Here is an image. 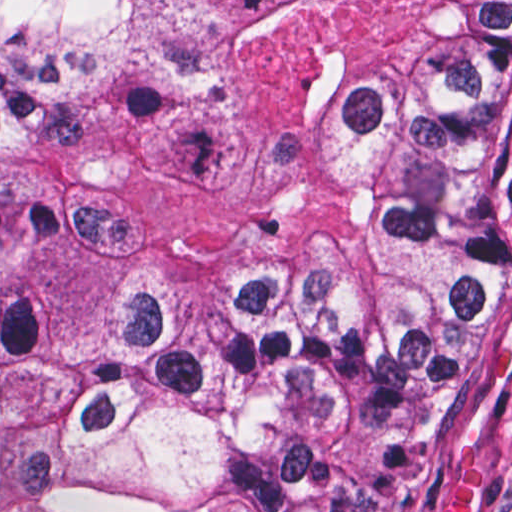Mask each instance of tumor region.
Listing matches in <instances>:
<instances>
[{"label": "tumor region", "instance_id": "obj_1", "mask_svg": "<svg viewBox=\"0 0 512 512\" xmlns=\"http://www.w3.org/2000/svg\"><path fill=\"white\" fill-rule=\"evenodd\" d=\"M511 209L512 1H0V512H367Z\"/></svg>", "mask_w": 512, "mask_h": 512}]
</instances>
